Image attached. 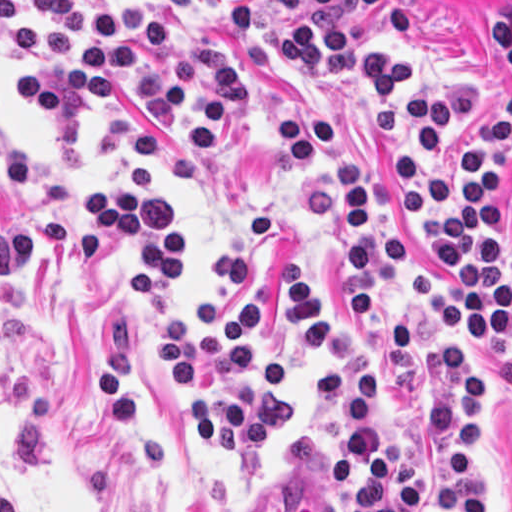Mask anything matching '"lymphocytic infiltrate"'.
I'll use <instances>...</instances> for the list:
<instances>
[{
	"label": "lymphocytic infiltrate",
	"mask_w": 512,
	"mask_h": 512,
	"mask_svg": "<svg viewBox=\"0 0 512 512\" xmlns=\"http://www.w3.org/2000/svg\"><path fill=\"white\" fill-rule=\"evenodd\" d=\"M0 34L20 56L45 53L21 73L14 95L34 121L59 119L113 95L141 100L190 151L226 144L247 111L244 72L212 41L171 34L158 11L129 0L107 17L79 0H0ZM350 79L376 141L386 150L403 223L440 255L442 278L413 256L395 231L372 235V177L346 157L348 121L311 103L278 131L294 160L311 169L320 150L335 162L333 184L304 195L320 231L347 230L350 315L374 319V245L403 288L446 315L440 327V395L424 406L426 427L445 451L443 512H482L475 474L486 359L512 350V271L489 201L512 155V93L459 143L453 174V101L471 75L410 68L384 34L357 38ZM271 240V215L258 211L237 247L216 266L198 307L179 293L190 284L186 214L142 160L85 193L60 215H0V278L20 252L65 254L87 264L121 259L129 302L140 304L153 338L149 367L181 397L202 445L222 459L254 460L291 428L289 366L277 330L320 366L308 381L310 407H339L337 448L326 480L348 512H407L419 503V470L405 442L394 392L393 426L383 424L373 354L352 322L323 304L289 268L259 299L229 298Z\"/></svg>",
	"instance_id": "obj_1"
}]
</instances>
